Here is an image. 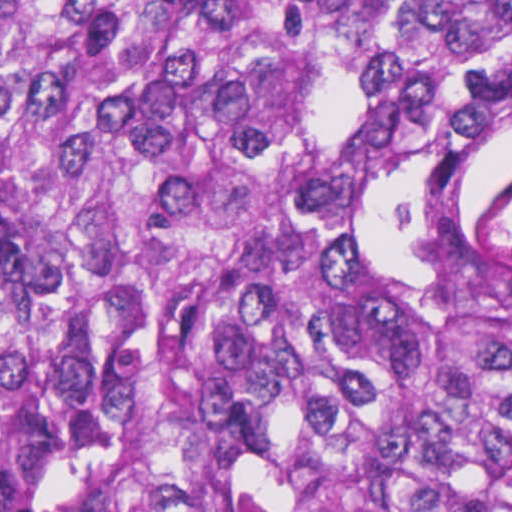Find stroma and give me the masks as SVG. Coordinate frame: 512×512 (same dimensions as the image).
<instances>
[{
    "mask_svg": "<svg viewBox=\"0 0 512 512\" xmlns=\"http://www.w3.org/2000/svg\"><path fill=\"white\" fill-rule=\"evenodd\" d=\"M0 512H49L44 506L0 489Z\"/></svg>",
    "mask_w": 512,
    "mask_h": 512,
    "instance_id": "obj_1",
    "label": "stroma"
}]
</instances>
